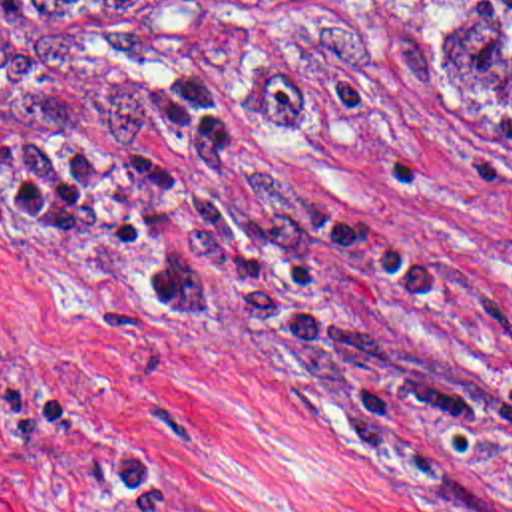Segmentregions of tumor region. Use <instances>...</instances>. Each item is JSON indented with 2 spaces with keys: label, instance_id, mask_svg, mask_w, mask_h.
Returning <instances> with one entry per match:
<instances>
[{
  "label": "tumor region",
  "instance_id": "1",
  "mask_svg": "<svg viewBox=\"0 0 512 512\" xmlns=\"http://www.w3.org/2000/svg\"><path fill=\"white\" fill-rule=\"evenodd\" d=\"M325 0H0V97L74 41L291 29ZM435 35L512 117V0H435ZM0 189L37 191L102 256L164 248L140 298L198 326L230 310L289 352L351 366L425 412L491 427L373 326L321 298L309 208L258 149L224 143V101L190 63L31 95L0 139Z\"/></svg>",
  "mask_w": 512,
  "mask_h": 512
}]
</instances>
